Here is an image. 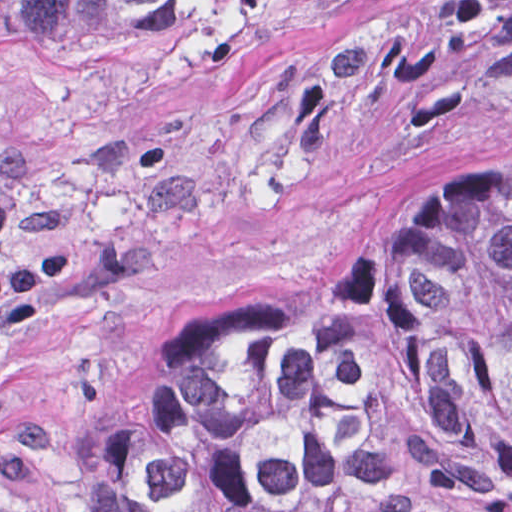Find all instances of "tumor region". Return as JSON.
<instances>
[{"label": "tumor region", "instance_id": "tumor-region-1", "mask_svg": "<svg viewBox=\"0 0 512 512\" xmlns=\"http://www.w3.org/2000/svg\"><path fill=\"white\" fill-rule=\"evenodd\" d=\"M246 0H0L38 44H133ZM97 512H512V163L154 345L92 421Z\"/></svg>", "mask_w": 512, "mask_h": 512}]
</instances>
